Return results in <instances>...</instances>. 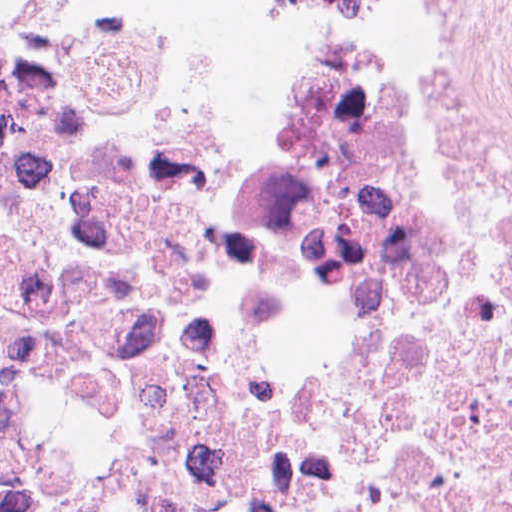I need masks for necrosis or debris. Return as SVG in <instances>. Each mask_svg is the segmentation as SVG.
I'll use <instances>...</instances> for the list:
<instances>
[{"label": "necrosis or debris", "mask_w": 512, "mask_h": 512, "mask_svg": "<svg viewBox=\"0 0 512 512\" xmlns=\"http://www.w3.org/2000/svg\"><path fill=\"white\" fill-rule=\"evenodd\" d=\"M0 0V512H512V0Z\"/></svg>", "instance_id": "4bbe7bcc"}]
</instances>
